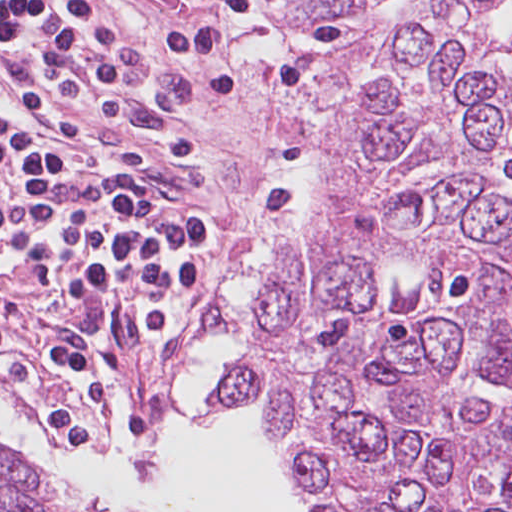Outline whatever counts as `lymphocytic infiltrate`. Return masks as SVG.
Masks as SVG:
<instances>
[{"mask_svg":"<svg viewBox=\"0 0 512 512\" xmlns=\"http://www.w3.org/2000/svg\"><path fill=\"white\" fill-rule=\"evenodd\" d=\"M161 1L182 18L188 87L284 86L288 56L256 0ZM0 55L75 123L162 121L136 94L127 40L96 0H0ZM93 139L101 157H40L0 142V273L10 262L26 271L42 309L97 333L141 421L178 390L191 328L210 307L207 165L183 138ZM46 318L54 363L93 422L59 409L49 429L95 433L105 373L72 329ZM4 345L0 337V356ZM0 384L16 394L1 371Z\"/></svg>","mask_w":512,"mask_h":512,"instance_id":"obj_1","label":"lymphocytic infiltrate"}]
</instances>
